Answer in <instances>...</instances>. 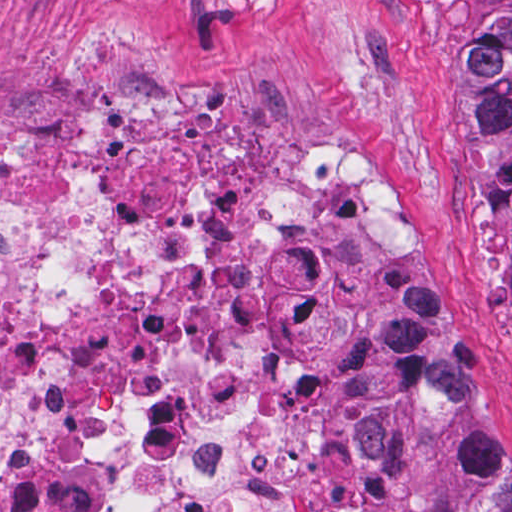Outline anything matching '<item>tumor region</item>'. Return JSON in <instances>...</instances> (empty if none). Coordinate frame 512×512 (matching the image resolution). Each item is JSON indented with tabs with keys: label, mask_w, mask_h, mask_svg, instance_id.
I'll return each instance as SVG.
<instances>
[{
	"label": "tumor region",
	"mask_w": 512,
	"mask_h": 512,
	"mask_svg": "<svg viewBox=\"0 0 512 512\" xmlns=\"http://www.w3.org/2000/svg\"><path fill=\"white\" fill-rule=\"evenodd\" d=\"M465 66L454 115L465 125L509 250L512 295V0H456ZM406 433L445 512H512V441L494 424L417 311L385 343Z\"/></svg>",
	"instance_id": "e687c5a6"
}]
</instances>
